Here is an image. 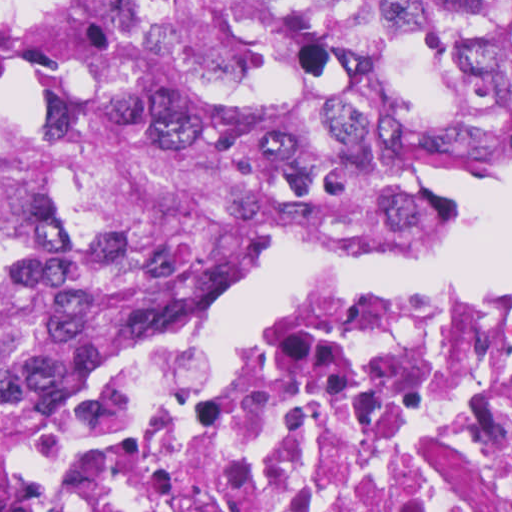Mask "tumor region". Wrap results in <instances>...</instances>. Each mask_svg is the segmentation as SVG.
I'll return each instance as SVG.
<instances>
[{"label":"tumor region","mask_w":512,"mask_h":512,"mask_svg":"<svg viewBox=\"0 0 512 512\" xmlns=\"http://www.w3.org/2000/svg\"><path fill=\"white\" fill-rule=\"evenodd\" d=\"M512 157V1L0 6V404L64 406L286 243L377 251Z\"/></svg>","instance_id":"tumor-region-1"}]
</instances>
